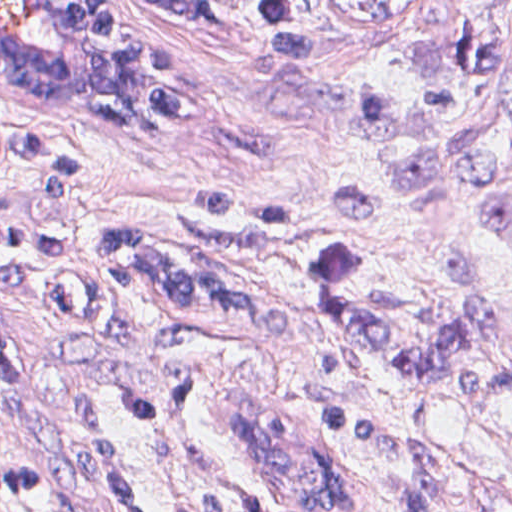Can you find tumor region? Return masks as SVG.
Listing matches in <instances>:
<instances>
[{
	"label": "tumor region",
	"instance_id": "1",
	"mask_svg": "<svg viewBox=\"0 0 512 512\" xmlns=\"http://www.w3.org/2000/svg\"><path fill=\"white\" fill-rule=\"evenodd\" d=\"M465 158L478 195L512 235V127L477 141ZM401 512H512V495L419 463L401 490Z\"/></svg>",
	"mask_w": 512,
	"mask_h": 512
}]
</instances>
